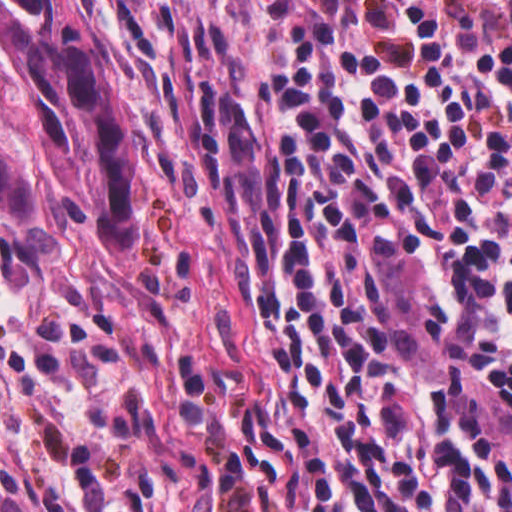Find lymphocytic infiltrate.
Listing matches in <instances>:
<instances>
[{
  "mask_svg": "<svg viewBox=\"0 0 512 512\" xmlns=\"http://www.w3.org/2000/svg\"><path fill=\"white\" fill-rule=\"evenodd\" d=\"M247 266L193 374L242 512H512V0H127Z\"/></svg>",
  "mask_w": 512,
  "mask_h": 512,
  "instance_id": "1",
  "label": "lymphocytic infiltrate"
}]
</instances>
